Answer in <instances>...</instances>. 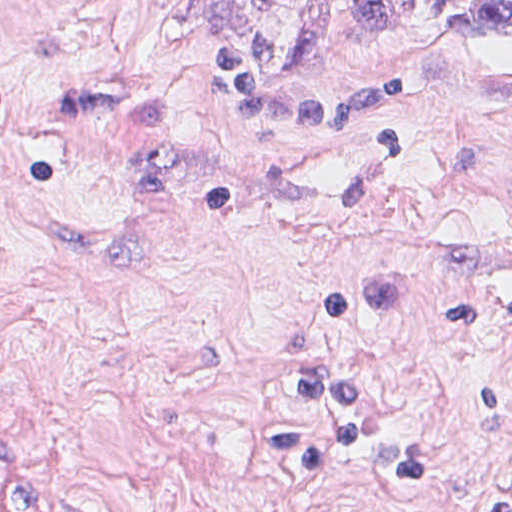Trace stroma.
<instances>
[{"mask_svg":"<svg viewBox=\"0 0 512 512\" xmlns=\"http://www.w3.org/2000/svg\"><path fill=\"white\" fill-rule=\"evenodd\" d=\"M444 0H0V512H512V33Z\"/></svg>","mask_w":512,"mask_h":512,"instance_id":"35a3bbf8","label":"stroma"}]
</instances>
